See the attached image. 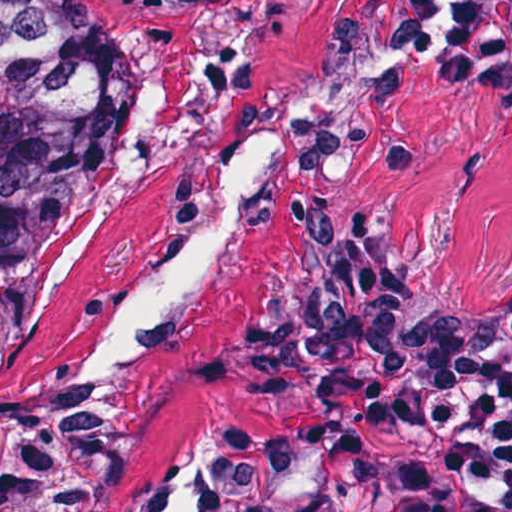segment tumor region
<instances>
[{
  "label": "tumor region",
  "instance_id": "obj_1",
  "mask_svg": "<svg viewBox=\"0 0 512 512\" xmlns=\"http://www.w3.org/2000/svg\"><path fill=\"white\" fill-rule=\"evenodd\" d=\"M116 0H0V349L33 327L62 225L126 109ZM483 66L512 80V2ZM512 324V273L481 302ZM0 512H114L110 390L0 408Z\"/></svg>",
  "mask_w": 512,
  "mask_h": 512
}]
</instances>
